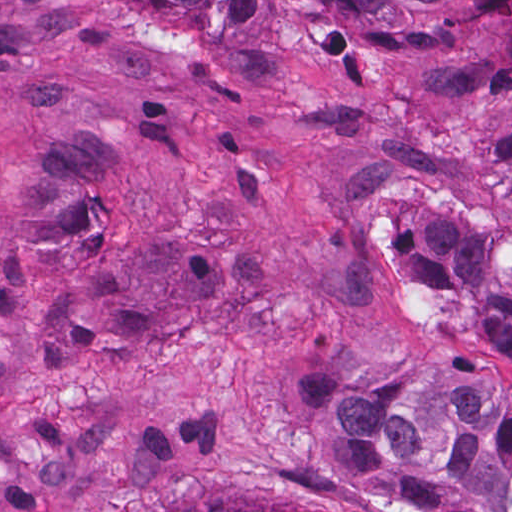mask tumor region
Listing matches in <instances>:
<instances>
[{
	"mask_svg": "<svg viewBox=\"0 0 512 512\" xmlns=\"http://www.w3.org/2000/svg\"><path fill=\"white\" fill-rule=\"evenodd\" d=\"M144 2L197 36L219 15L283 39L289 0ZM352 34L394 43L455 32L467 46L418 79L430 99L512 83V0H338ZM383 242L403 352L398 361L298 349L283 364L294 428L314 466L390 512H512V130L464 137V194L442 207L390 201ZM229 512H340L259 502Z\"/></svg>",
	"mask_w": 512,
	"mask_h": 512,
	"instance_id": "1",
	"label": "tumor region"
}]
</instances>
